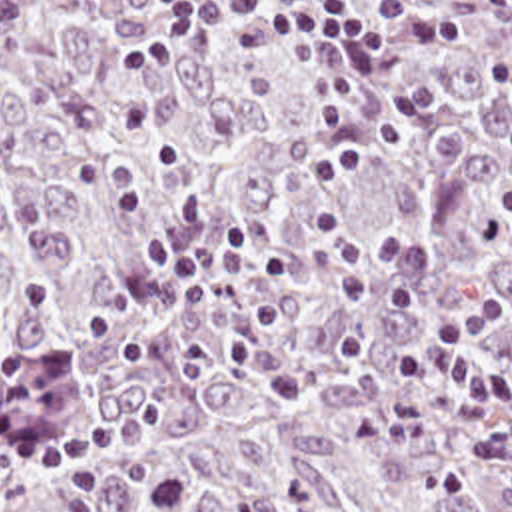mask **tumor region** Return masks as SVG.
Here are the masks:
<instances>
[{
  "label": "tumor region",
  "mask_w": 512,
  "mask_h": 512,
  "mask_svg": "<svg viewBox=\"0 0 512 512\" xmlns=\"http://www.w3.org/2000/svg\"><path fill=\"white\" fill-rule=\"evenodd\" d=\"M330 2L378 26L390 0ZM422 2L462 30L408 56L426 120L360 74L398 142L342 190L352 260L372 294L416 292L406 350L502 304L482 360L510 390L394 445L376 410L440 384L396 376L374 316L314 260L324 142L300 56L240 22L124 72L158 0H0V512H512V38ZM230 220L292 250L276 332L248 328L252 266L162 280L140 256ZM140 392L158 410L138 441L39 465Z\"/></svg>",
  "instance_id": "tumor-region-1"
}]
</instances>
